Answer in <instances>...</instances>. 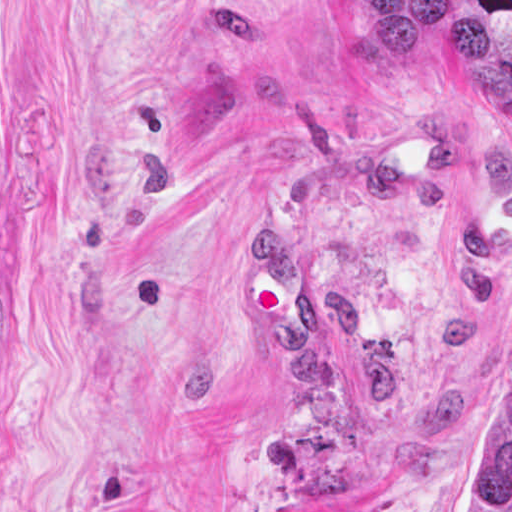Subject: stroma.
<instances>
[{
  "instance_id": "1",
  "label": "stroma",
  "mask_w": 512,
  "mask_h": 512,
  "mask_svg": "<svg viewBox=\"0 0 512 512\" xmlns=\"http://www.w3.org/2000/svg\"><path fill=\"white\" fill-rule=\"evenodd\" d=\"M512 364V0H0V512H466Z\"/></svg>"
}]
</instances>
